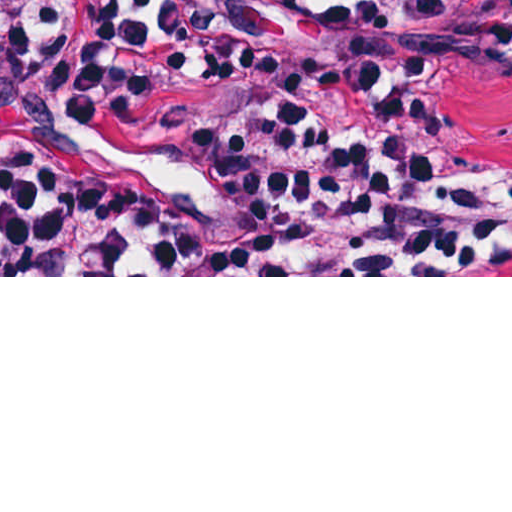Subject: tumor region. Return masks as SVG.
Wrapping results in <instances>:
<instances>
[{
	"label": "tumor region",
	"instance_id": "1",
	"mask_svg": "<svg viewBox=\"0 0 512 512\" xmlns=\"http://www.w3.org/2000/svg\"><path fill=\"white\" fill-rule=\"evenodd\" d=\"M124 1L129 0H0V28L98 14ZM331 25L351 41L408 58L421 72L445 135L512 182V59L408 32L386 0H332ZM78 125L45 113L1 119L0 173ZM495 275H512V268Z\"/></svg>",
	"mask_w": 512,
	"mask_h": 512
}]
</instances>
